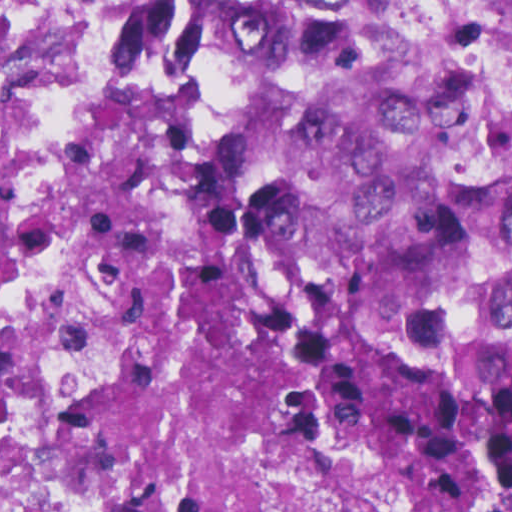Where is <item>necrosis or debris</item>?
<instances>
[{
    "instance_id": "1",
    "label": "necrosis or debris",
    "mask_w": 512,
    "mask_h": 512,
    "mask_svg": "<svg viewBox=\"0 0 512 512\" xmlns=\"http://www.w3.org/2000/svg\"><path fill=\"white\" fill-rule=\"evenodd\" d=\"M116 29L117 0H0V104L84 111ZM87 239L38 242L0 288V512H166Z\"/></svg>"
}]
</instances>
